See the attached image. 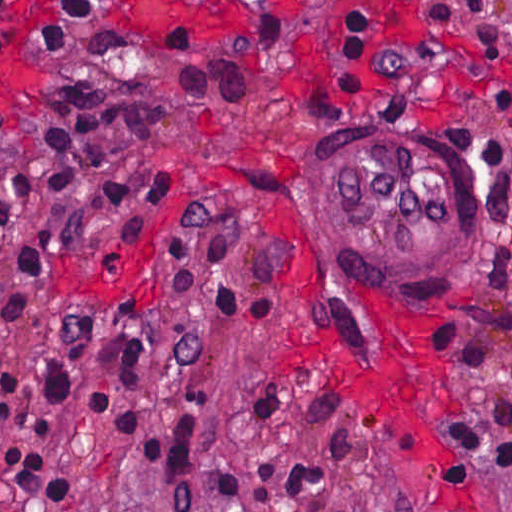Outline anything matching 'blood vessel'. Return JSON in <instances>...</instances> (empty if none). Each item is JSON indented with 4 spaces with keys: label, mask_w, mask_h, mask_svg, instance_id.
Instances as JSON below:
<instances>
[{
    "label": "blood vessel",
    "mask_w": 512,
    "mask_h": 512,
    "mask_svg": "<svg viewBox=\"0 0 512 512\" xmlns=\"http://www.w3.org/2000/svg\"><path fill=\"white\" fill-rule=\"evenodd\" d=\"M314 227L324 259L356 297L407 313L468 303L493 251L481 194L435 163L352 131L330 143Z\"/></svg>",
    "instance_id": "blood-vessel-1"
}]
</instances>
